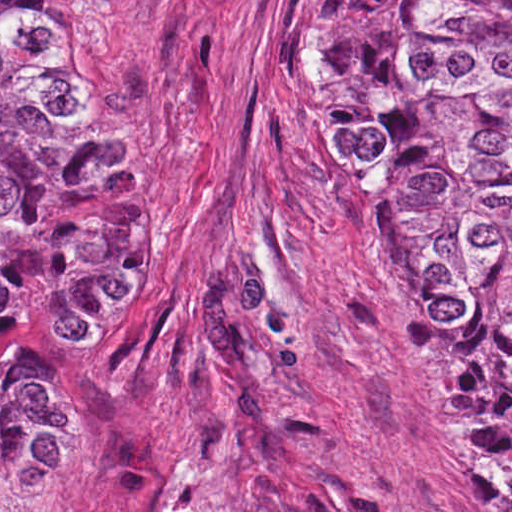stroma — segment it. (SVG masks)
<instances>
[{
  "instance_id": "35a3bbf8",
  "label": "stroma",
  "mask_w": 512,
  "mask_h": 512,
  "mask_svg": "<svg viewBox=\"0 0 512 512\" xmlns=\"http://www.w3.org/2000/svg\"><path fill=\"white\" fill-rule=\"evenodd\" d=\"M323 0H51L121 52L159 185L142 284L18 303L0 362L64 395L76 462L0 512H504L378 238V175L330 145Z\"/></svg>"
}]
</instances>
